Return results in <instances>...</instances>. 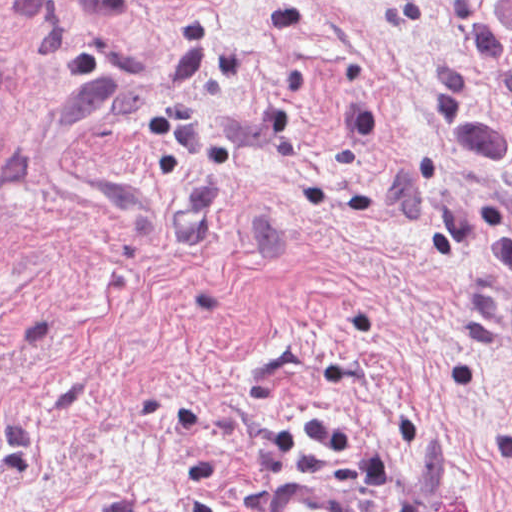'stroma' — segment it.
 Instances as JSON below:
<instances>
[{"label": "stroma", "instance_id": "stroma-1", "mask_svg": "<svg viewBox=\"0 0 512 512\" xmlns=\"http://www.w3.org/2000/svg\"><path fill=\"white\" fill-rule=\"evenodd\" d=\"M491 22L0 0V512H512Z\"/></svg>", "mask_w": 512, "mask_h": 512}]
</instances>
